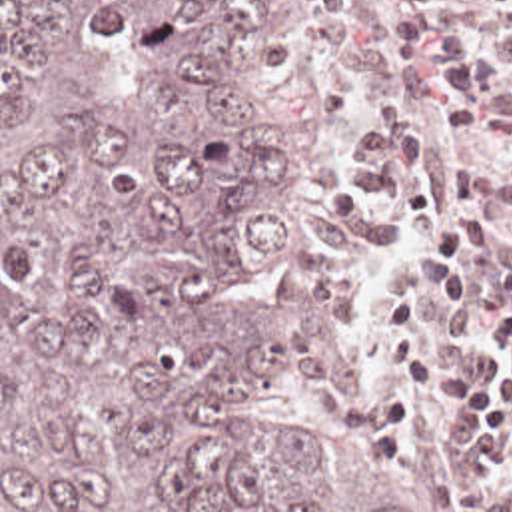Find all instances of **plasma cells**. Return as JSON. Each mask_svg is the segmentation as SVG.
<instances>
[{"label":"plasma cells","mask_w":512,"mask_h":512,"mask_svg":"<svg viewBox=\"0 0 512 512\" xmlns=\"http://www.w3.org/2000/svg\"><path fill=\"white\" fill-rule=\"evenodd\" d=\"M287 87L417 466L512 512V0H347Z\"/></svg>","instance_id":"obj_1"}]
</instances>
